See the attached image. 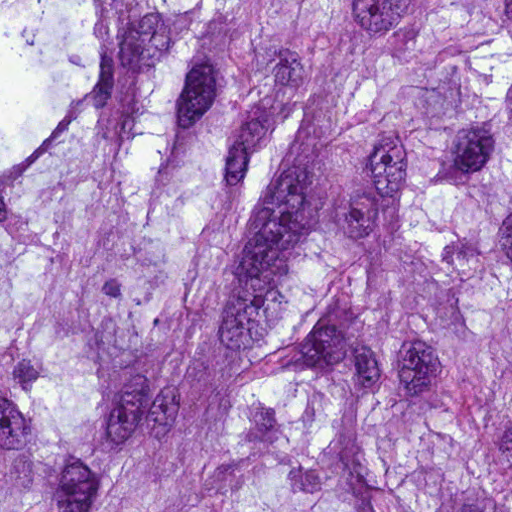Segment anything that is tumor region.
Segmentation results:
<instances>
[{
  "label": "tumor region",
  "mask_w": 512,
  "mask_h": 512,
  "mask_svg": "<svg viewBox=\"0 0 512 512\" xmlns=\"http://www.w3.org/2000/svg\"><path fill=\"white\" fill-rule=\"evenodd\" d=\"M0 512H512V0H0Z\"/></svg>",
  "instance_id": "1"
}]
</instances>
